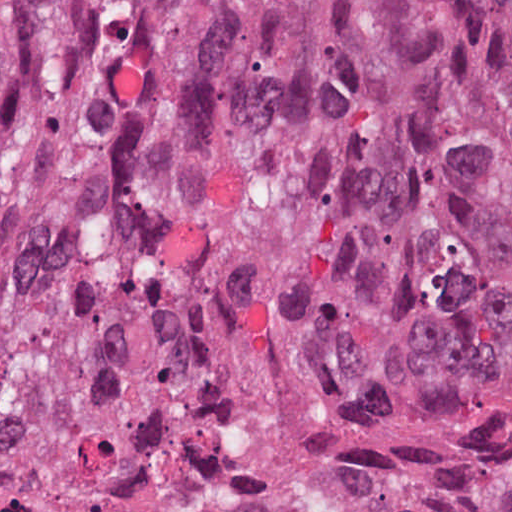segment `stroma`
Instances as JSON below:
<instances>
[{"instance_id":"1","label":"stroma","mask_w":512,"mask_h":512,"mask_svg":"<svg viewBox=\"0 0 512 512\" xmlns=\"http://www.w3.org/2000/svg\"><path fill=\"white\" fill-rule=\"evenodd\" d=\"M54 2L28 0L9 38L0 48V97L11 85ZM511 356L512 287L504 301L467 342L411 374L394 388L342 405L302 425L236 429L217 437L212 443L245 445L251 453V468L327 443L345 441L378 425L462 399L491 384Z\"/></svg>"}]
</instances>
